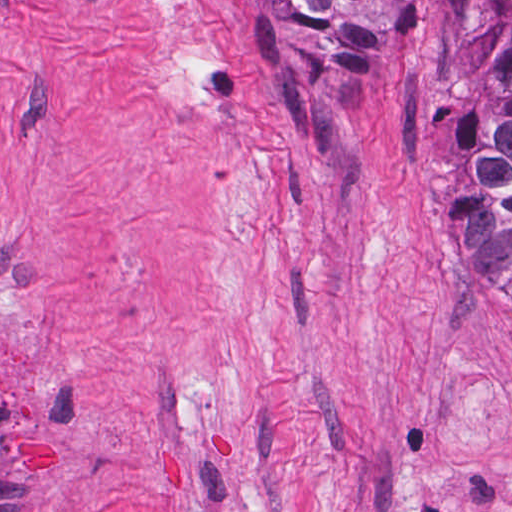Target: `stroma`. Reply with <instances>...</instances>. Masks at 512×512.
I'll list each match as a JSON object with an SVG mask.
<instances>
[{"label":"stroma","instance_id":"35a3bbf8","mask_svg":"<svg viewBox=\"0 0 512 512\" xmlns=\"http://www.w3.org/2000/svg\"><path fill=\"white\" fill-rule=\"evenodd\" d=\"M456 52L432 0H0V512H512Z\"/></svg>","mask_w":512,"mask_h":512}]
</instances>
